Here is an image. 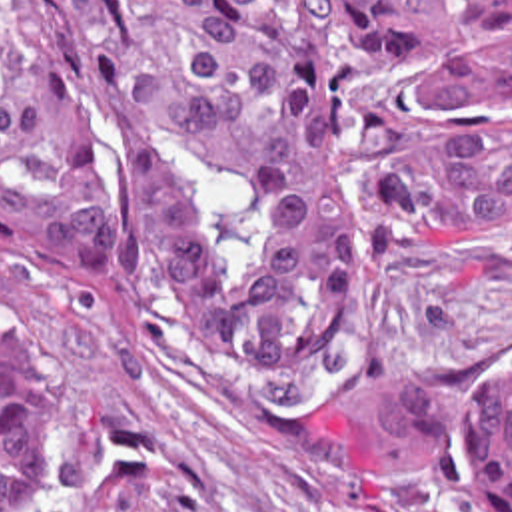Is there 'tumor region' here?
<instances>
[{
    "instance_id": "1",
    "label": "tumor region",
    "mask_w": 512,
    "mask_h": 512,
    "mask_svg": "<svg viewBox=\"0 0 512 512\" xmlns=\"http://www.w3.org/2000/svg\"><path fill=\"white\" fill-rule=\"evenodd\" d=\"M512 0H0V236L57 268L170 272L204 370L302 378L398 260L512 218ZM512 512V382L482 398ZM51 448L0 356V512Z\"/></svg>"
}]
</instances>
